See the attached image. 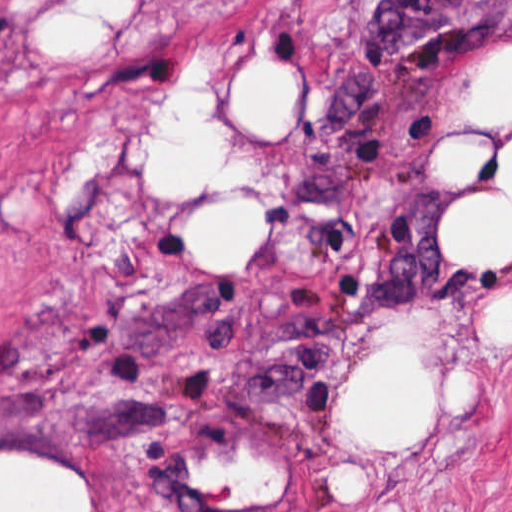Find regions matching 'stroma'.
<instances>
[{"instance_id": "35a3bbf8", "label": "stroma", "mask_w": 512, "mask_h": 512, "mask_svg": "<svg viewBox=\"0 0 512 512\" xmlns=\"http://www.w3.org/2000/svg\"><path fill=\"white\" fill-rule=\"evenodd\" d=\"M70 7L100 32L50 49L38 20ZM511 49L512 0H0V459L74 470L91 512H512V333L487 326L512 260L448 249L452 216L512 208V110L471 109ZM257 60L298 84L279 134L228 100ZM180 91L224 147L165 200L156 130ZM102 116L118 152L55 210ZM444 144L476 146L466 176L440 166ZM233 204L263 212L261 244L207 265L193 222ZM403 344L427 426L373 444L343 395ZM244 457L275 493L197 473Z\"/></svg>"}]
</instances>
